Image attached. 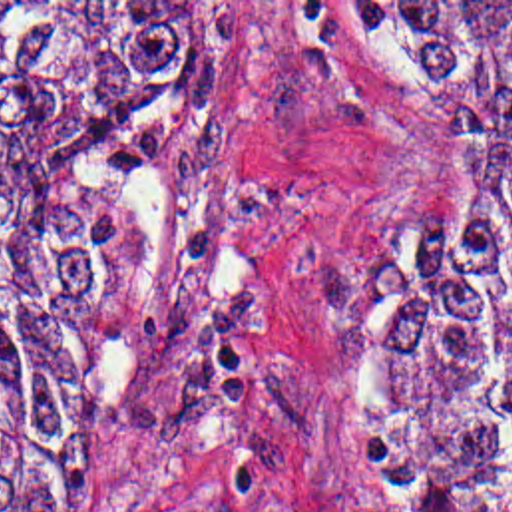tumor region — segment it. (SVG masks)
I'll use <instances>...</instances> for the list:
<instances>
[{
	"instance_id": "1",
	"label": "tumor region",
	"mask_w": 512,
	"mask_h": 512,
	"mask_svg": "<svg viewBox=\"0 0 512 512\" xmlns=\"http://www.w3.org/2000/svg\"><path fill=\"white\" fill-rule=\"evenodd\" d=\"M323 4L431 173L327 408L399 512H512V2ZM230 62L232 2H0V512H82L68 398L128 273L132 181Z\"/></svg>"
}]
</instances>
